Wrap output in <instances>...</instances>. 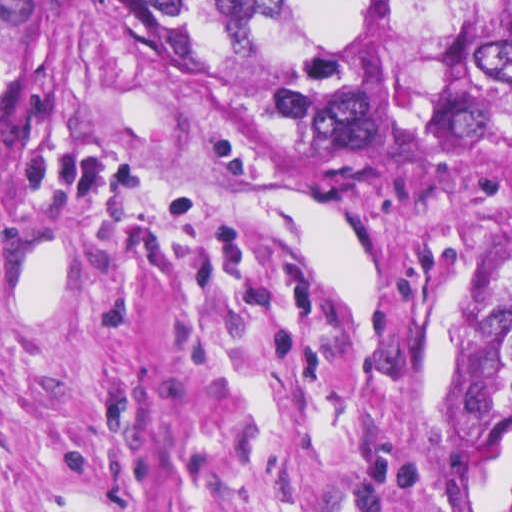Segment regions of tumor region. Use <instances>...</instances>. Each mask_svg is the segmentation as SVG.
<instances>
[{
  "instance_id": "e687c5a6",
  "label": "tumor region",
  "mask_w": 512,
  "mask_h": 512,
  "mask_svg": "<svg viewBox=\"0 0 512 512\" xmlns=\"http://www.w3.org/2000/svg\"><path fill=\"white\" fill-rule=\"evenodd\" d=\"M181 46L301 137L405 167L512 157V0H81ZM464 403L512 431V240L480 296Z\"/></svg>"
}]
</instances>
